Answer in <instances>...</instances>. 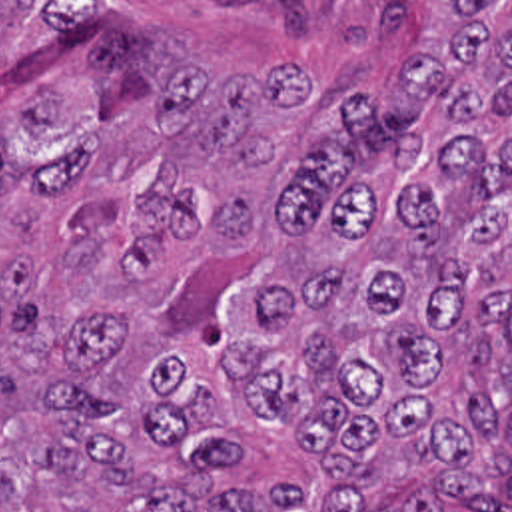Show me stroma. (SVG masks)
I'll return each instance as SVG.
<instances>
[{
    "label": "stroma",
    "instance_id": "stroma-1",
    "mask_svg": "<svg viewBox=\"0 0 512 512\" xmlns=\"http://www.w3.org/2000/svg\"><path fill=\"white\" fill-rule=\"evenodd\" d=\"M199 43L269 53L336 91H374L444 39L452 0H103ZM490 512H512V498Z\"/></svg>",
    "mask_w": 512,
    "mask_h": 512
}]
</instances>
